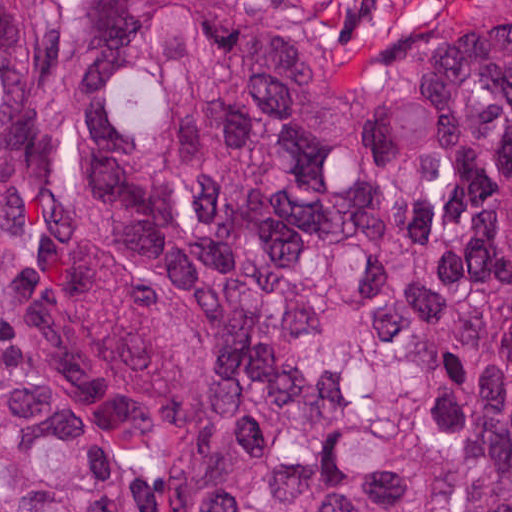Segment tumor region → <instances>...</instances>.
Instances as JSON below:
<instances>
[{"label": "tumor region", "mask_w": 512, "mask_h": 512, "mask_svg": "<svg viewBox=\"0 0 512 512\" xmlns=\"http://www.w3.org/2000/svg\"><path fill=\"white\" fill-rule=\"evenodd\" d=\"M512 512V0L395 83L295 0H0V512Z\"/></svg>", "instance_id": "obj_1"}]
</instances>
